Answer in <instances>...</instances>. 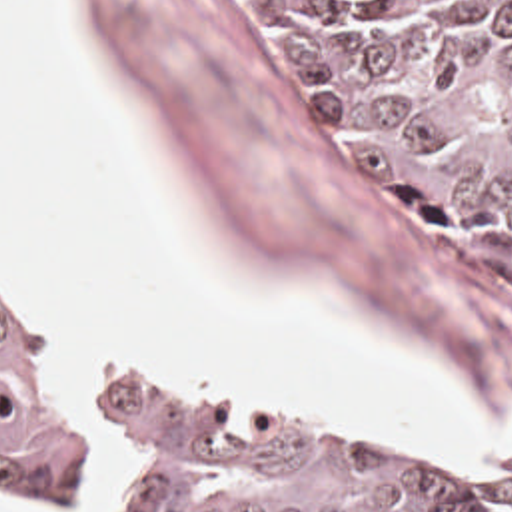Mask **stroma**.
<instances>
[{
	"label": "stroma",
	"mask_w": 512,
	"mask_h": 512,
	"mask_svg": "<svg viewBox=\"0 0 512 512\" xmlns=\"http://www.w3.org/2000/svg\"><path fill=\"white\" fill-rule=\"evenodd\" d=\"M70 1L134 135L234 275L378 323L458 371L488 423L510 429L512 283L416 237L344 175L246 1ZM0 279L48 315L76 401L120 371L82 367L64 311L22 279L2 247ZM122 369L174 375L144 361ZM200 385L406 462L466 472L512 498V450L498 466H466L236 385ZM92 444L104 450L94 421ZM118 480V512H134L130 456L112 436L98 502L42 508L18 502L2 482L0 502L22 512H84L106 502Z\"/></svg>",
	"instance_id": "1"
}]
</instances>
